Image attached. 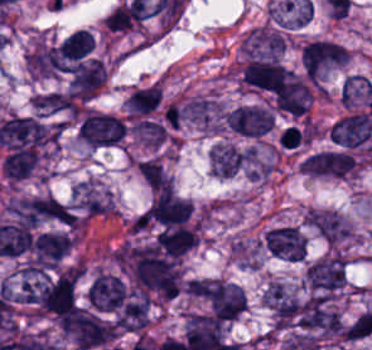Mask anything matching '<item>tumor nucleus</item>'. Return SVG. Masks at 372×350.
Instances as JSON below:
<instances>
[{
    "label": "tumor nucleus",
    "instance_id": "tumor-nucleus-1",
    "mask_svg": "<svg viewBox=\"0 0 372 350\" xmlns=\"http://www.w3.org/2000/svg\"><path fill=\"white\" fill-rule=\"evenodd\" d=\"M346 280V258L339 253L324 255L303 272V283L312 294L328 295L339 291Z\"/></svg>",
    "mask_w": 372,
    "mask_h": 350
},
{
    "label": "tumor nucleus",
    "instance_id": "tumor-nucleus-2",
    "mask_svg": "<svg viewBox=\"0 0 372 350\" xmlns=\"http://www.w3.org/2000/svg\"><path fill=\"white\" fill-rule=\"evenodd\" d=\"M242 80L256 89L279 94L296 81V74L276 59L254 57L245 65Z\"/></svg>",
    "mask_w": 372,
    "mask_h": 350
},
{
    "label": "tumor nucleus",
    "instance_id": "tumor-nucleus-3",
    "mask_svg": "<svg viewBox=\"0 0 372 350\" xmlns=\"http://www.w3.org/2000/svg\"><path fill=\"white\" fill-rule=\"evenodd\" d=\"M203 297L218 321H236L245 312V292L224 280L213 279Z\"/></svg>",
    "mask_w": 372,
    "mask_h": 350
},
{
    "label": "tumor nucleus",
    "instance_id": "tumor-nucleus-4",
    "mask_svg": "<svg viewBox=\"0 0 372 350\" xmlns=\"http://www.w3.org/2000/svg\"><path fill=\"white\" fill-rule=\"evenodd\" d=\"M347 60L345 46L322 38L305 42L300 51V66L303 71H330Z\"/></svg>",
    "mask_w": 372,
    "mask_h": 350
},
{
    "label": "tumor nucleus",
    "instance_id": "tumor-nucleus-5",
    "mask_svg": "<svg viewBox=\"0 0 372 350\" xmlns=\"http://www.w3.org/2000/svg\"><path fill=\"white\" fill-rule=\"evenodd\" d=\"M69 201L82 219L112 212L110 193L93 180L86 178L71 187Z\"/></svg>",
    "mask_w": 372,
    "mask_h": 350
},
{
    "label": "tumor nucleus",
    "instance_id": "tumor-nucleus-6",
    "mask_svg": "<svg viewBox=\"0 0 372 350\" xmlns=\"http://www.w3.org/2000/svg\"><path fill=\"white\" fill-rule=\"evenodd\" d=\"M265 253L288 262H301L306 251L305 239L291 225L273 226L263 233Z\"/></svg>",
    "mask_w": 372,
    "mask_h": 350
},
{
    "label": "tumor nucleus",
    "instance_id": "tumor-nucleus-7",
    "mask_svg": "<svg viewBox=\"0 0 372 350\" xmlns=\"http://www.w3.org/2000/svg\"><path fill=\"white\" fill-rule=\"evenodd\" d=\"M329 139L346 148L362 145L372 135V110L345 115L328 129Z\"/></svg>",
    "mask_w": 372,
    "mask_h": 350
},
{
    "label": "tumor nucleus",
    "instance_id": "tumor-nucleus-8",
    "mask_svg": "<svg viewBox=\"0 0 372 350\" xmlns=\"http://www.w3.org/2000/svg\"><path fill=\"white\" fill-rule=\"evenodd\" d=\"M230 129L247 138H259L266 134L274 123V117L263 108L253 105H240L225 114Z\"/></svg>",
    "mask_w": 372,
    "mask_h": 350
},
{
    "label": "tumor nucleus",
    "instance_id": "tumor-nucleus-9",
    "mask_svg": "<svg viewBox=\"0 0 372 350\" xmlns=\"http://www.w3.org/2000/svg\"><path fill=\"white\" fill-rule=\"evenodd\" d=\"M127 294V288L121 278L98 271L87 290L86 297L96 310L115 311Z\"/></svg>",
    "mask_w": 372,
    "mask_h": 350
},
{
    "label": "tumor nucleus",
    "instance_id": "tumor-nucleus-10",
    "mask_svg": "<svg viewBox=\"0 0 372 350\" xmlns=\"http://www.w3.org/2000/svg\"><path fill=\"white\" fill-rule=\"evenodd\" d=\"M226 110L207 95H193L184 103L183 118L202 130L224 128Z\"/></svg>",
    "mask_w": 372,
    "mask_h": 350
},
{
    "label": "tumor nucleus",
    "instance_id": "tumor-nucleus-11",
    "mask_svg": "<svg viewBox=\"0 0 372 350\" xmlns=\"http://www.w3.org/2000/svg\"><path fill=\"white\" fill-rule=\"evenodd\" d=\"M106 78V67L98 59L81 61L72 69L68 90L86 101L98 93Z\"/></svg>",
    "mask_w": 372,
    "mask_h": 350
},
{
    "label": "tumor nucleus",
    "instance_id": "tumor-nucleus-12",
    "mask_svg": "<svg viewBox=\"0 0 372 350\" xmlns=\"http://www.w3.org/2000/svg\"><path fill=\"white\" fill-rule=\"evenodd\" d=\"M72 243L60 233H40L30 244L29 264L43 269L57 265Z\"/></svg>",
    "mask_w": 372,
    "mask_h": 350
},
{
    "label": "tumor nucleus",
    "instance_id": "tumor-nucleus-13",
    "mask_svg": "<svg viewBox=\"0 0 372 350\" xmlns=\"http://www.w3.org/2000/svg\"><path fill=\"white\" fill-rule=\"evenodd\" d=\"M81 130L82 142L98 148L120 145L127 137V133L86 112L81 117Z\"/></svg>",
    "mask_w": 372,
    "mask_h": 350
},
{
    "label": "tumor nucleus",
    "instance_id": "tumor-nucleus-14",
    "mask_svg": "<svg viewBox=\"0 0 372 350\" xmlns=\"http://www.w3.org/2000/svg\"><path fill=\"white\" fill-rule=\"evenodd\" d=\"M208 164L217 178H231L242 166V151L231 143L217 142L208 154Z\"/></svg>",
    "mask_w": 372,
    "mask_h": 350
},
{
    "label": "tumor nucleus",
    "instance_id": "tumor-nucleus-15",
    "mask_svg": "<svg viewBox=\"0 0 372 350\" xmlns=\"http://www.w3.org/2000/svg\"><path fill=\"white\" fill-rule=\"evenodd\" d=\"M299 167L308 176L342 178L341 154L333 151L308 154Z\"/></svg>",
    "mask_w": 372,
    "mask_h": 350
},
{
    "label": "tumor nucleus",
    "instance_id": "tumor-nucleus-16",
    "mask_svg": "<svg viewBox=\"0 0 372 350\" xmlns=\"http://www.w3.org/2000/svg\"><path fill=\"white\" fill-rule=\"evenodd\" d=\"M160 95V87L153 83L130 91L122 105L131 114L146 115L156 109Z\"/></svg>",
    "mask_w": 372,
    "mask_h": 350
},
{
    "label": "tumor nucleus",
    "instance_id": "tumor-nucleus-17",
    "mask_svg": "<svg viewBox=\"0 0 372 350\" xmlns=\"http://www.w3.org/2000/svg\"><path fill=\"white\" fill-rule=\"evenodd\" d=\"M328 245L339 247L351 238V226L343 216L318 210Z\"/></svg>",
    "mask_w": 372,
    "mask_h": 350
},
{
    "label": "tumor nucleus",
    "instance_id": "tumor-nucleus-18",
    "mask_svg": "<svg viewBox=\"0 0 372 350\" xmlns=\"http://www.w3.org/2000/svg\"><path fill=\"white\" fill-rule=\"evenodd\" d=\"M94 48V40L87 29L69 33L61 44V54L68 61H78Z\"/></svg>",
    "mask_w": 372,
    "mask_h": 350
}]
</instances>
